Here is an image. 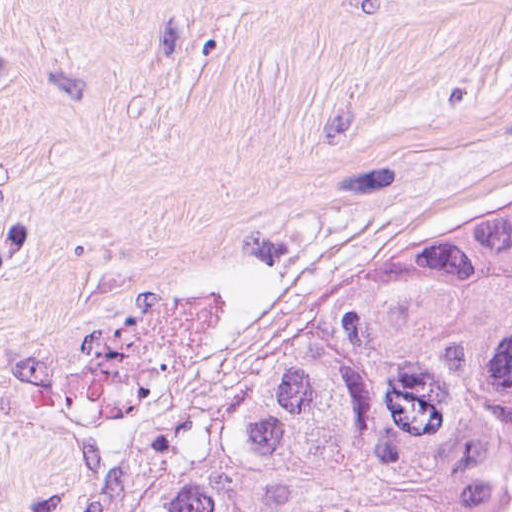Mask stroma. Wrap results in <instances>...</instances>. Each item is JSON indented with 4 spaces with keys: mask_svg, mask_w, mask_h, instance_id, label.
<instances>
[{
    "mask_svg": "<svg viewBox=\"0 0 512 512\" xmlns=\"http://www.w3.org/2000/svg\"><path fill=\"white\" fill-rule=\"evenodd\" d=\"M495 180L512 0H0V512H124Z\"/></svg>",
    "mask_w": 512,
    "mask_h": 512,
    "instance_id": "35a3bbf8",
    "label": "stroma"
}]
</instances>
